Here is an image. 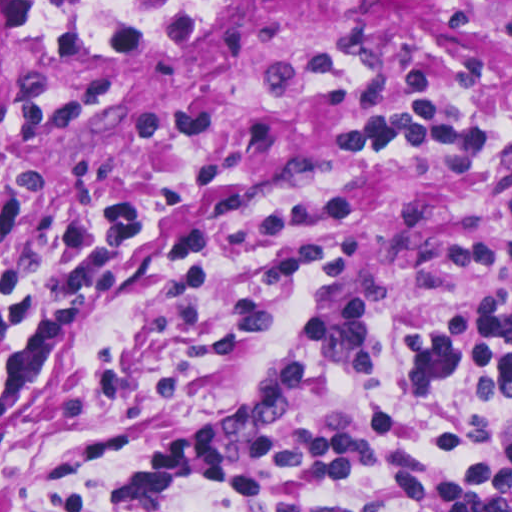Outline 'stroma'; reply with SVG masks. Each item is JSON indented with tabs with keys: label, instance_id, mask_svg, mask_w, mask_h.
<instances>
[{
	"label": "stroma",
	"instance_id": "1",
	"mask_svg": "<svg viewBox=\"0 0 512 512\" xmlns=\"http://www.w3.org/2000/svg\"><path fill=\"white\" fill-rule=\"evenodd\" d=\"M436 1L512 0H0V191L21 203L35 266L57 267L52 225L83 201L131 191L142 205L127 266L0 424V512H116L159 408L184 427L226 419L287 343L320 357L354 418L396 407L444 446L476 386L413 399L393 306L371 308V374L297 320L352 230L341 297L358 303L512 279V168L368 150L357 135L512 68V34ZM188 512L227 511L202 490Z\"/></svg>",
	"mask_w": 512,
	"mask_h": 512
}]
</instances>
